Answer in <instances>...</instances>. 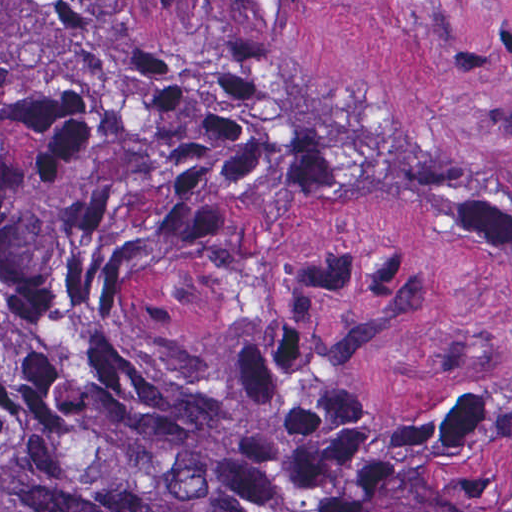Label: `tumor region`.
<instances>
[{
    "label": "tumor region",
    "mask_w": 512,
    "mask_h": 512,
    "mask_svg": "<svg viewBox=\"0 0 512 512\" xmlns=\"http://www.w3.org/2000/svg\"><path fill=\"white\" fill-rule=\"evenodd\" d=\"M482 162L155 53L127 0H0V512H512V366L448 418L401 417L292 351L182 346L112 258L319 168L475 220L512 292V190Z\"/></svg>",
    "instance_id": "obj_1"
}]
</instances>
